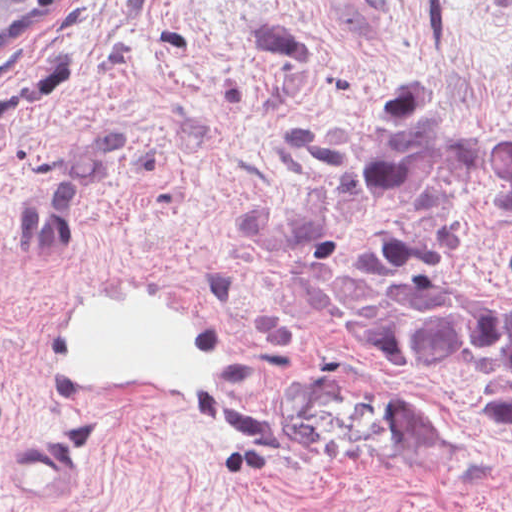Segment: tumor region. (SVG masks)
I'll return each instance as SVG.
<instances>
[{"mask_svg": "<svg viewBox=\"0 0 512 512\" xmlns=\"http://www.w3.org/2000/svg\"><path fill=\"white\" fill-rule=\"evenodd\" d=\"M425 84L374 81L341 136L255 191L248 246L325 336L385 367L480 386L512 425V294L458 284L449 261L458 200L512 214V134L471 131Z\"/></svg>", "mask_w": 512, "mask_h": 512, "instance_id": "tumor-region-1", "label": "tumor region"}]
</instances>
